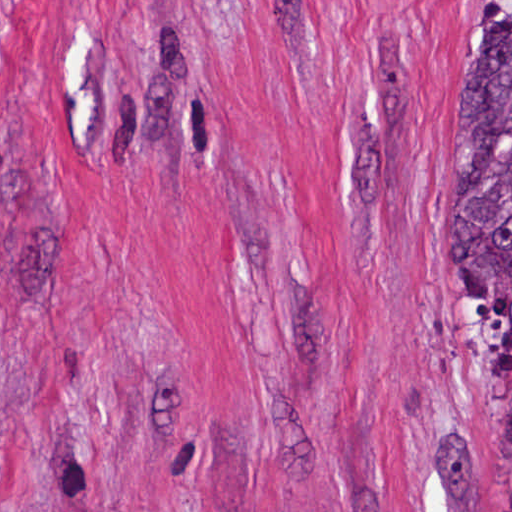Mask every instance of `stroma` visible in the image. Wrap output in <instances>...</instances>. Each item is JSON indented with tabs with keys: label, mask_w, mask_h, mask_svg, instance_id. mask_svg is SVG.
<instances>
[{
	"label": "stroma",
	"mask_w": 512,
	"mask_h": 512,
	"mask_svg": "<svg viewBox=\"0 0 512 512\" xmlns=\"http://www.w3.org/2000/svg\"><path fill=\"white\" fill-rule=\"evenodd\" d=\"M510 16L0 0V512H503L450 115Z\"/></svg>",
	"instance_id": "stroma-1"
}]
</instances>
